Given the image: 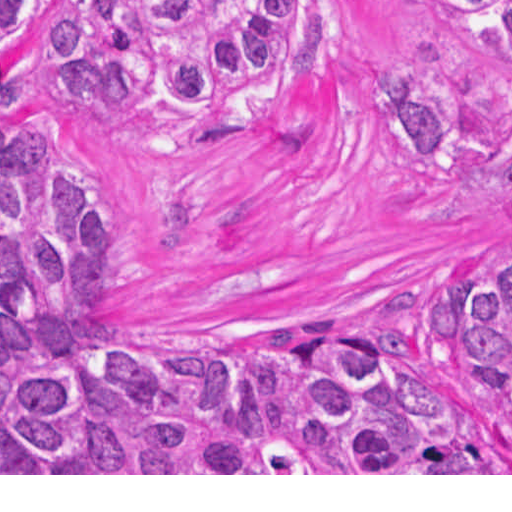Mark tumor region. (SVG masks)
Listing matches in <instances>:
<instances>
[{
	"label": "tumor region",
	"mask_w": 512,
	"mask_h": 512,
	"mask_svg": "<svg viewBox=\"0 0 512 512\" xmlns=\"http://www.w3.org/2000/svg\"><path fill=\"white\" fill-rule=\"evenodd\" d=\"M50 0H0V41ZM512 74V0H443ZM312 0H70L34 24L35 87L76 114L123 100L226 113L299 88ZM404 162L470 137L437 76L374 70ZM61 142L0 120V473H512L382 331L309 313L269 350H132L129 226ZM463 376L512 435V261L432 281Z\"/></svg>",
	"instance_id": "e687c5a6"
}]
</instances>
